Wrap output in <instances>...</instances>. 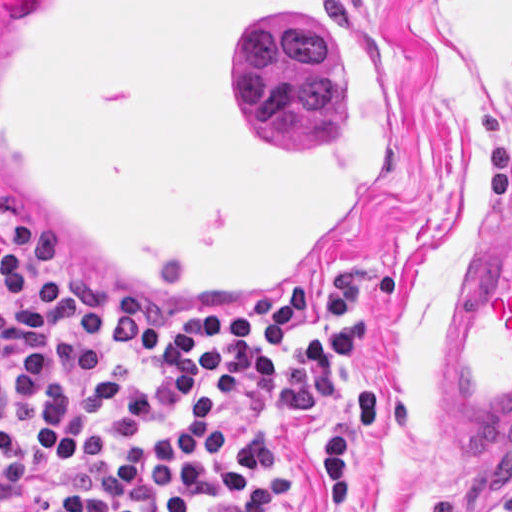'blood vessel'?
<instances>
[{
	"label": "blood vessel",
	"instance_id": "obj_1",
	"mask_svg": "<svg viewBox=\"0 0 512 512\" xmlns=\"http://www.w3.org/2000/svg\"><path fill=\"white\" fill-rule=\"evenodd\" d=\"M414 100L339 0H6L0 203L80 279L285 311L402 188ZM512 443V215L467 258L444 409Z\"/></svg>",
	"mask_w": 512,
	"mask_h": 512
}]
</instances>
